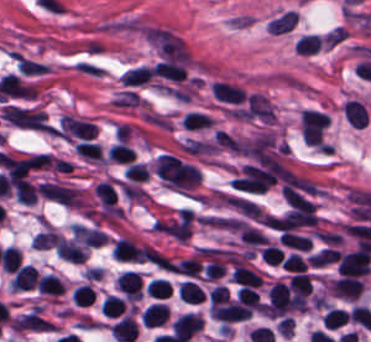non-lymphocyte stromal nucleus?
Returning a JSON list of instances; mask_svg holds the SVG:
<instances>
[{"label":"non-lymphocyte stromal nucleus","mask_w":371,"mask_h":342,"mask_svg":"<svg viewBox=\"0 0 371 342\" xmlns=\"http://www.w3.org/2000/svg\"><path fill=\"white\" fill-rule=\"evenodd\" d=\"M73 66L79 73L91 78H102L106 71V68L91 59L80 58Z\"/></svg>","instance_id":"dd21d789"}]
</instances>
